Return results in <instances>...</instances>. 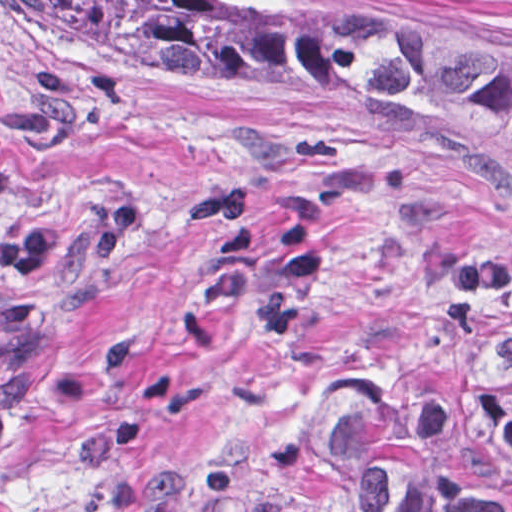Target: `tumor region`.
I'll return each mask as SVG.
<instances>
[{"label": "tumor region", "mask_w": 512, "mask_h": 512, "mask_svg": "<svg viewBox=\"0 0 512 512\" xmlns=\"http://www.w3.org/2000/svg\"><path fill=\"white\" fill-rule=\"evenodd\" d=\"M19 1L128 62L358 107L512 192V52L308 29L217 0ZM120 249L121 219L98 204L0 179V448L40 363L14 293ZM233 512H512V329L447 408L419 420L353 402L288 408Z\"/></svg>", "instance_id": "obj_1"}]
</instances>
